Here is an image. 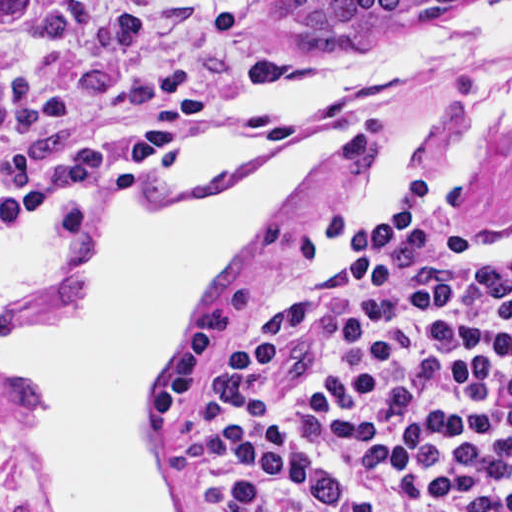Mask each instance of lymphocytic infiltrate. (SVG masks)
Segmentation results:
<instances>
[{
	"mask_svg": "<svg viewBox=\"0 0 512 512\" xmlns=\"http://www.w3.org/2000/svg\"><path fill=\"white\" fill-rule=\"evenodd\" d=\"M431 197L338 282L212 342L200 512H512V249L434 234Z\"/></svg>",
	"mask_w": 512,
	"mask_h": 512,
	"instance_id": "f902f5d3",
	"label": "lymphocytic infiltrate"
}]
</instances>
